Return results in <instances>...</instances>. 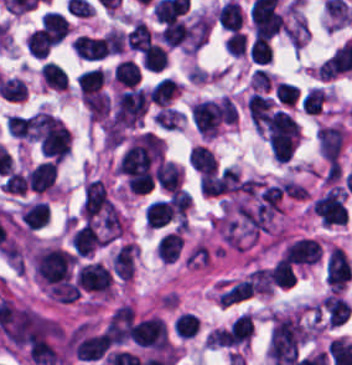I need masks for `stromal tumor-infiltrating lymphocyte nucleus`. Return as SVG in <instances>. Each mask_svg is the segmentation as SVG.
Instances as JSON below:
<instances>
[{
  "mask_svg": "<svg viewBox=\"0 0 352 365\" xmlns=\"http://www.w3.org/2000/svg\"><path fill=\"white\" fill-rule=\"evenodd\" d=\"M306 339L298 313L272 318L269 349L274 363L288 364L298 354Z\"/></svg>",
  "mask_w": 352,
  "mask_h": 365,
  "instance_id": "stromal-tumor-infiltrating-lymphocyte-nucleus-1",
  "label": "stromal tumor-infiltrating lymphocyte nucleus"
},
{
  "mask_svg": "<svg viewBox=\"0 0 352 365\" xmlns=\"http://www.w3.org/2000/svg\"><path fill=\"white\" fill-rule=\"evenodd\" d=\"M265 128L272 155L287 160L299 139L296 120L284 110L275 109L267 114Z\"/></svg>",
  "mask_w": 352,
  "mask_h": 365,
  "instance_id": "stromal-tumor-infiltrating-lymphocyte-nucleus-2",
  "label": "stromal tumor-infiltrating lymphocyte nucleus"
},
{
  "mask_svg": "<svg viewBox=\"0 0 352 365\" xmlns=\"http://www.w3.org/2000/svg\"><path fill=\"white\" fill-rule=\"evenodd\" d=\"M32 259L36 273L45 282L57 284L68 278L73 256L61 247H41Z\"/></svg>",
  "mask_w": 352,
  "mask_h": 365,
  "instance_id": "stromal-tumor-infiltrating-lymphocyte-nucleus-3",
  "label": "stromal tumor-infiltrating lymphocyte nucleus"
},
{
  "mask_svg": "<svg viewBox=\"0 0 352 365\" xmlns=\"http://www.w3.org/2000/svg\"><path fill=\"white\" fill-rule=\"evenodd\" d=\"M223 98L201 99L192 106L194 123L201 135H215L224 115Z\"/></svg>",
  "mask_w": 352,
  "mask_h": 365,
  "instance_id": "stromal-tumor-infiltrating-lymphocyte-nucleus-4",
  "label": "stromal tumor-infiltrating lymphocyte nucleus"
},
{
  "mask_svg": "<svg viewBox=\"0 0 352 365\" xmlns=\"http://www.w3.org/2000/svg\"><path fill=\"white\" fill-rule=\"evenodd\" d=\"M131 337L134 344L143 348L165 349V323L156 317H149L133 323Z\"/></svg>",
  "mask_w": 352,
  "mask_h": 365,
  "instance_id": "stromal-tumor-infiltrating-lymphocyte-nucleus-5",
  "label": "stromal tumor-infiltrating lymphocyte nucleus"
},
{
  "mask_svg": "<svg viewBox=\"0 0 352 365\" xmlns=\"http://www.w3.org/2000/svg\"><path fill=\"white\" fill-rule=\"evenodd\" d=\"M75 279L82 288L97 292H108L111 285L110 271L96 261H88L78 266Z\"/></svg>",
  "mask_w": 352,
  "mask_h": 365,
  "instance_id": "stromal-tumor-infiltrating-lymphocyte-nucleus-6",
  "label": "stromal tumor-infiltrating lymphocyte nucleus"
},
{
  "mask_svg": "<svg viewBox=\"0 0 352 365\" xmlns=\"http://www.w3.org/2000/svg\"><path fill=\"white\" fill-rule=\"evenodd\" d=\"M250 19L255 37L270 38L284 26L279 13L272 7L265 5L252 4Z\"/></svg>",
  "mask_w": 352,
  "mask_h": 365,
  "instance_id": "stromal-tumor-infiltrating-lymphocyte-nucleus-7",
  "label": "stromal tumor-infiltrating lymphocyte nucleus"
},
{
  "mask_svg": "<svg viewBox=\"0 0 352 365\" xmlns=\"http://www.w3.org/2000/svg\"><path fill=\"white\" fill-rule=\"evenodd\" d=\"M133 311L132 306L122 304L112 313L105 331L114 344H122L129 338Z\"/></svg>",
  "mask_w": 352,
  "mask_h": 365,
  "instance_id": "stromal-tumor-infiltrating-lymphocyte-nucleus-8",
  "label": "stromal tumor-infiltrating lymphocyte nucleus"
},
{
  "mask_svg": "<svg viewBox=\"0 0 352 365\" xmlns=\"http://www.w3.org/2000/svg\"><path fill=\"white\" fill-rule=\"evenodd\" d=\"M71 47L75 54L86 59H101L109 52L106 37L81 33L73 37Z\"/></svg>",
  "mask_w": 352,
  "mask_h": 365,
  "instance_id": "stromal-tumor-infiltrating-lymphocyte-nucleus-9",
  "label": "stromal tumor-infiltrating lymphocyte nucleus"
},
{
  "mask_svg": "<svg viewBox=\"0 0 352 365\" xmlns=\"http://www.w3.org/2000/svg\"><path fill=\"white\" fill-rule=\"evenodd\" d=\"M318 144L324 157L337 164L344 132L335 125H322L317 133Z\"/></svg>",
  "mask_w": 352,
  "mask_h": 365,
  "instance_id": "stromal-tumor-infiltrating-lymphocyte-nucleus-10",
  "label": "stromal tumor-infiltrating lymphocyte nucleus"
},
{
  "mask_svg": "<svg viewBox=\"0 0 352 365\" xmlns=\"http://www.w3.org/2000/svg\"><path fill=\"white\" fill-rule=\"evenodd\" d=\"M57 164L55 160H47L32 168L27 177L26 185L30 190L43 193L50 190L56 177Z\"/></svg>",
  "mask_w": 352,
  "mask_h": 365,
  "instance_id": "stromal-tumor-infiltrating-lymphocyte-nucleus-11",
  "label": "stromal tumor-infiltrating lymphocyte nucleus"
},
{
  "mask_svg": "<svg viewBox=\"0 0 352 365\" xmlns=\"http://www.w3.org/2000/svg\"><path fill=\"white\" fill-rule=\"evenodd\" d=\"M157 183L159 187L167 191H173L179 187L180 167L172 160H164L154 168Z\"/></svg>",
  "mask_w": 352,
  "mask_h": 365,
  "instance_id": "stromal-tumor-infiltrating-lymphocyte-nucleus-12",
  "label": "stromal tumor-infiltrating lymphocyte nucleus"
},
{
  "mask_svg": "<svg viewBox=\"0 0 352 365\" xmlns=\"http://www.w3.org/2000/svg\"><path fill=\"white\" fill-rule=\"evenodd\" d=\"M183 245L184 239L180 232L169 231L158 240L155 250L165 262H173Z\"/></svg>",
  "mask_w": 352,
  "mask_h": 365,
  "instance_id": "stromal-tumor-infiltrating-lymphocyte-nucleus-13",
  "label": "stromal tumor-infiltrating lymphocyte nucleus"
},
{
  "mask_svg": "<svg viewBox=\"0 0 352 365\" xmlns=\"http://www.w3.org/2000/svg\"><path fill=\"white\" fill-rule=\"evenodd\" d=\"M270 102L271 98L252 92L246 103L250 121L260 131L267 119Z\"/></svg>",
  "mask_w": 352,
  "mask_h": 365,
  "instance_id": "stromal-tumor-infiltrating-lymphocyte-nucleus-14",
  "label": "stromal tumor-infiltrating lymphocyte nucleus"
},
{
  "mask_svg": "<svg viewBox=\"0 0 352 365\" xmlns=\"http://www.w3.org/2000/svg\"><path fill=\"white\" fill-rule=\"evenodd\" d=\"M171 210L168 199H154L144 210V219L148 227H159L169 221Z\"/></svg>",
  "mask_w": 352,
  "mask_h": 365,
  "instance_id": "stromal-tumor-infiltrating-lymphocyte-nucleus-15",
  "label": "stromal tumor-infiltrating lymphocyte nucleus"
},
{
  "mask_svg": "<svg viewBox=\"0 0 352 365\" xmlns=\"http://www.w3.org/2000/svg\"><path fill=\"white\" fill-rule=\"evenodd\" d=\"M178 90V83L170 77H163L148 92L152 103L166 106Z\"/></svg>",
  "mask_w": 352,
  "mask_h": 365,
  "instance_id": "stromal-tumor-infiltrating-lymphocyte-nucleus-16",
  "label": "stromal tumor-infiltrating lymphocyte nucleus"
},
{
  "mask_svg": "<svg viewBox=\"0 0 352 365\" xmlns=\"http://www.w3.org/2000/svg\"><path fill=\"white\" fill-rule=\"evenodd\" d=\"M189 164L195 170L214 174L217 167L215 155L206 147L197 144L190 150Z\"/></svg>",
  "mask_w": 352,
  "mask_h": 365,
  "instance_id": "stromal-tumor-infiltrating-lymphocyte-nucleus-17",
  "label": "stromal tumor-infiltrating lymphocyte nucleus"
},
{
  "mask_svg": "<svg viewBox=\"0 0 352 365\" xmlns=\"http://www.w3.org/2000/svg\"><path fill=\"white\" fill-rule=\"evenodd\" d=\"M243 14L235 0H228L219 8L218 19L221 27L234 31L241 27Z\"/></svg>",
  "mask_w": 352,
  "mask_h": 365,
  "instance_id": "stromal-tumor-infiltrating-lymphocyte-nucleus-18",
  "label": "stromal tumor-infiltrating lymphocyte nucleus"
},
{
  "mask_svg": "<svg viewBox=\"0 0 352 365\" xmlns=\"http://www.w3.org/2000/svg\"><path fill=\"white\" fill-rule=\"evenodd\" d=\"M49 213L46 204L41 201H34L26 204L20 215L30 228H38L47 223Z\"/></svg>",
  "mask_w": 352,
  "mask_h": 365,
  "instance_id": "stromal-tumor-infiltrating-lymphocyte-nucleus-19",
  "label": "stromal tumor-infiltrating lymphocyte nucleus"
},
{
  "mask_svg": "<svg viewBox=\"0 0 352 365\" xmlns=\"http://www.w3.org/2000/svg\"><path fill=\"white\" fill-rule=\"evenodd\" d=\"M168 61V53L156 42H151L142 52L144 68L152 71H160Z\"/></svg>",
  "mask_w": 352,
  "mask_h": 365,
  "instance_id": "stromal-tumor-infiltrating-lymphocyte-nucleus-20",
  "label": "stromal tumor-infiltrating lymphocyte nucleus"
},
{
  "mask_svg": "<svg viewBox=\"0 0 352 365\" xmlns=\"http://www.w3.org/2000/svg\"><path fill=\"white\" fill-rule=\"evenodd\" d=\"M41 21L56 43L65 37L68 22L60 11H46Z\"/></svg>",
  "mask_w": 352,
  "mask_h": 365,
  "instance_id": "stromal-tumor-infiltrating-lymphocyte-nucleus-21",
  "label": "stromal tumor-infiltrating lymphocyte nucleus"
},
{
  "mask_svg": "<svg viewBox=\"0 0 352 365\" xmlns=\"http://www.w3.org/2000/svg\"><path fill=\"white\" fill-rule=\"evenodd\" d=\"M113 77L120 83L130 87L140 79V68L137 62L132 59L123 58L117 62Z\"/></svg>",
  "mask_w": 352,
  "mask_h": 365,
  "instance_id": "stromal-tumor-infiltrating-lymphocyte-nucleus-22",
  "label": "stromal tumor-infiltrating lymphocyte nucleus"
},
{
  "mask_svg": "<svg viewBox=\"0 0 352 365\" xmlns=\"http://www.w3.org/2000/svg\"><path fill=\"white\" fill-rule=\"evenodd\" d=\"M152 36L149 27L142 21H138L125 35L126 45L136 51H143L150 42Z\"/></svg>",
  "mask_w": 352,
  "mask_h": 365,
  "instance_id": "stromal-tumor-infiltrating-lymphocyte-nucleus-23",
  "label": "stromal tumor-infiltrating lymphocyte nucleus"
},
{
  "mask_svg": "<svg viewBox=\"0 0 352 365\" xmlns=\"http://www.w3.org/2000/svg\"><path fill=\"white\" fill-rule=\"evenodd\" d=\"M42 82L54 88H67V74L64 69L52 61H45L40 66Z\"/></svg>",
  "mask_w": 352,
  "mask_h": 365,
  "instance_id": "stromal-tumor-infiltrating-lymphocyte-nucleus-24",
  "label": "stromal tumor-infiltrating lymphocyte nucleus"
},
{
  "mask_svg": "<svg viewBox=\"0 0 352 365\" xmlns=\"http://www.w3.org/2000/svg\"><path fill=\"white\" fill-rule=\"evenodd\" d=\"M53 40L48 32L41 26L32 30L26 38V47L34 57H42L45 55Z\"/></svg>",
  "mask_w": 352,
  "mask_h": 365,
  "instance_id": "stromal-tumor-infiltrating-lymphocyte-nucleus-25",
  "label": "stromal tumor-infiltrating lymphocyte nucleus"
},
{
  "mask_svg": "<svg viewBox=\"0 0 352 365\" xmlns=\"http://www.w3.org/2000/svg\"><path fill=\"white\" fill-rule=\"evenodd\" d=\"M103 80V72L98 68H91L76 79L80 99L99 89Z\"/></svg>",
  "mask_w": 352,
  "mask_h": 365,
  "instance_id": "stromal-tumor-infiltrating-lymphocyte-nucleus-26",
  "label": "stromal tumor-infiltrating lymphocyte nucleus"
},
{
  "mask_svg": "<svg viewBox=\"0 0 352 365\" xmlns=\"http://www.w3.org/2000/svg\"><path fill=\"white\" fill-rule=\"evenodd\" d=\"M269 279L277 285L289 287L296 281V272L291 262L280 257L272 266Z\"/></svg>",
  "mask_w": 352,
  "mask_h": 365,
  "instance_id": "stromal-tumor-infiltrating-lymphocyte-nucleus-27",
  "label": "stromal tumor-infiltrating lymphocyte nucleus"
},
{
  "mask_svg": "<svg viewBox=\"0 0 352 365\" xmlns=\"http://www.w3.org/2000/svg\"><path fill=\"white\" fill-rule=\"evenodd\" d=\"M253 294L251 285L245 281H237L226 289L219 297L220 303L225 307Z\"/></svg>",
  "mask_w": 352,
  "mask_h": 365,
  "instance_id": "stromal-tumor-infiltrating-lymphocyte-nucleus-28",
  "label": "stromal tumor-infiltrating lymphocyte nucleus"
},
{
  "mask_svg": "<svg viewBox=\"0 0 352 365\" xmlns=\"http://www.w3.org/2000/svg\"><path fill=\"white\" fill-rule=\"evenodd\" d=\"M191 196L188 190L174 189L169 195L172 213L185 220L190 207Z\"/></svg>",
  "mask_w": 352,
  "mask_h": 365,
  "instance_id": "stromal-tumor-infiltrating-lymphocyte-nucleus-29",
  "label": "stromal tumor-infiltrating lymphocyte nucleus"
},
{
  "mask_svg": "<svg viewBox=\"0 0 352 365\" xmlns=\"http://www.w3.org/2000/svg\"><path fill=\"white\" fill-rule=\"evenodd\" d=\"M249 55L251 61L257 64L271 62L272 50L267 38L254 37Z\"/></svg>",
  "mask_w": 352,
  "mask_h": 365,
  "instance_id": "stromal-tumor-infiltrating-lymphocyte-nucleus-30",
  "label": "stromal tumor-infiltrating lymphocyte nucleus"
},
{
  "mask_svg": "<svg viewBox=\"0 0 352 365\" xmlns=\"http://www.w3.org/2000/svg\"><path fill=\"white\" fill-rule=\"evenodd\" d=\"M0 89L4 99L22 100L26 97V87L17 77L6 78L1 82Z\"/></svg>",
  "mask_w": 352,
  "mask_h": 365,
  "instance_id": "stromal-tumor-infiltrating-lymphocyte-nucleus-31",
  "label": "stromal tumor-infiltrating lymphocyte nucleus"
},
{
  "mask_svg": "<svg viewBox=\"0 0 352 365\" xmlns=\"http://www.w3.org/2000/svg\"><path fill=\"white\" fill-rule=\"evenodd\" d=\"M186 22L181 20H174L167 22L162 30L161 35L163 38L172 45H177L185 41Z\"/></svg>",
  "mask_w": 352,
  "mask_h": 365,
  "instance_id": "stromal-tumor-infiltrating-lymphocyte-nucleus-32",
  "label": "stromal tumor-infiltrating lymphocyte nucleus"
},
{
  "mask_svg": "<svg viewBox=\"0 0 352 365\" xmlns=\"http://www.w3.org/2000/svg\"><path fill=\"white\" fill-rule=\"evenodd\" d=\"M197 316L194 312H180L175 318L177 335L187 337L196 331Z\"/></svg>",
  "mask_w": 352,
  "mask_h": 365,
  "instance_id": "stromal-tumor-infiltrating-lymphocyte-nucleus-33",
  "label": "stromal tumor-infiltrating lymphocyte nucleus"
},
{
  "mask_svg": "<svg viewBox=\"0 0 352 365\" xmlns=\"http://www.w3.org/2000/svg\"><path fill=\"white\" fill-rule=\"evenodd\" d=\"M327 94L318 87H311L302 102L303 110L308 113H317L325 101Z\"/></svg>",
  "mask_w": 352,
  "mask_h": 365,
  "instance_id": "stromal-tumor-infiltrating-lymphocyte-nucleus-34",
  "label": "stromal tumor-infiltrating lymphocyte nucleus"
},
{
  "mask_svg": "<svg viewBox=\"0 0 352 365\" xmlns=\"http://www.w3.org/2000/svg\"><path fill=\"white\" fill-rule=\"evenodd\" d=\"M298 91L299 87L296 84L278 81L276 84L275 96L280 103L294 105Z\"/></svg>",
  "mask_w": 352,
  "mask_h": 365,
  "instance_id": "stromal-tumor-infiltrating-lymphocyte-nucleus-35",
  "label": "stromal tumor-infiltrating lymphocyte nucleus"
},
{
  "mask_svg": "<svg viewBox=\"0 0 352 365\" xmlns=\"http://www.w3.org/2000/svg\"><path fill=\"white\" fill-rule=\"evenodd\" d=\"M225 49L236 56L245 54L246 49V35L241 31H234L226 38Z\"/></svg>",
  "mask_w": 352,
  "mask_h": 365,
  "instance_id": "stromal-tumor-infiltrating-lymphocyte-nucleus-36",
  "label": "stromal tumor-infiltrating lymphocyte nucleus"
},
{
  "mask_svg": "<svg viewBox=\"0 0 352 365\" xmlns=\"http://www.w3.org/2000/svg\"><path fill=\"white\" fill-rule=\"evenodd\" d=\"M5 185H6V190L25 194L26 179L24 175L18 173L15 170L8 175L5 181Z\"/></svg>",
  "mask_w": 352,
  "mask_h": 365,
  "instance_id": "stromal-tumor-infiltrating-lymphocyte-nucleus-37",
  "label": "stromal tumor-infiltrating lymphocyte nucleus"
}]
</instances>
